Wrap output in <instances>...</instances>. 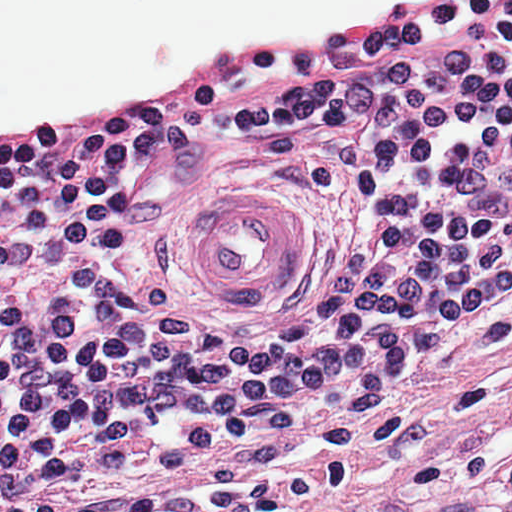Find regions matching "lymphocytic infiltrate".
<instances>
[{
	"instance_id": "obj_1",
	"label": "lymphocytic infiltrate",
	"mask_w": 512,
	"mask_h": 512,
	"mask_svg": "<svg viewBox=\"0 0 512 512\" xmlns=\"http://www.w3.org/2000/svg\"><path fill=\"white\" fill-rule=\"evenodd\" d=\"M258 56L285 80L254 140L386 221L296 321L244 338L174 309L133 177L143 147L195 141V94L0 133V512L221 495L512 311V0H406Z\"/></svg>"
}]
</instances>
